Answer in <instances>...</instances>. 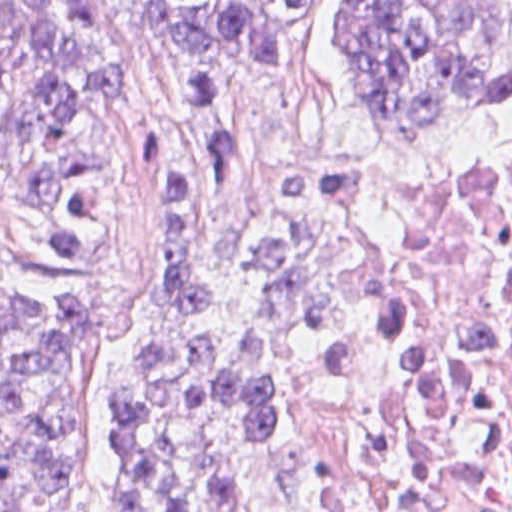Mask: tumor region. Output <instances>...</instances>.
<instances>
[{
    "mask_svg": "<svg viewBox=\"0 0 512 512\" xmlns=\"http://www.w3.org/2000/svg\"><path fill=\"white\" fill-rule=\"evenodd\" d=\"M321 2L0 0V182L28 199L49 260L89 264L114 240L111 169L95 153L48 154L76 128L115 47L151 26L209 51L282 57ZM355 4L362 105L388 140L464 138L512 113L508 5ZM141 177L160 241V321L114 407L118 511L260 512L302 378L355 293L294 222L206 250L199 180L161 130L144 134ZM95 346L81 301L0 283V512L73 505L75 393ZM458 476L446 428L390 402L311 512H403Z\"/></svg>",
    "mask_w": 512,
    "mask_h": 512,
    "instance_id": "tumor-region-1",
    "label": "tumor region"
}]
</instances>
